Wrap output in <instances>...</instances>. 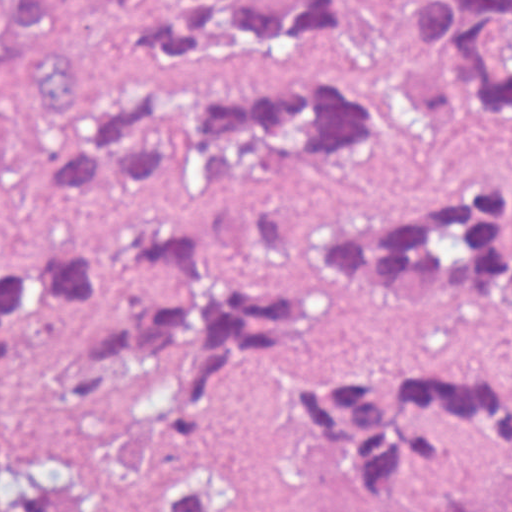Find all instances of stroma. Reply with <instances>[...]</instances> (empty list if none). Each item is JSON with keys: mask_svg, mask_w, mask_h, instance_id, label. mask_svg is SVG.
Returning <instances> with one entry per match:
<instances>
[{"mask_svg": "<svg viewBox=\"0 0 512 512\" xmlns=\"http://www.w3.org/2000/svg\"><path fill=\"white\" fill-rule=\"evenodd\" d=\"M439 181L503 185L512 227V128L472 122L434 143L360 146L348 164L316 178H236L125 203L60 204L37 190L13 71L0 49V251L180 224L243 266L308 288L311 326L279 361L327 372L512 376V311L478 292L395 299L323 275L308 259L322 219L338 207ZM88 328L50 320L13 364H0V440L47 512H151L77 455L70 440L53 378L71 339ZM95 427L100 439L131 456L208 468L235 512L478 511L512 490V474L482 450L399 507H360L308 463L294 431L247 399L216 404L204 420L192 405L121 390L109 394Z\"/></svg>", "mask_w": 512, "mask_h": 512, "instance_id": "35a3bbf8", "label": "stroma"}]
</instances>
